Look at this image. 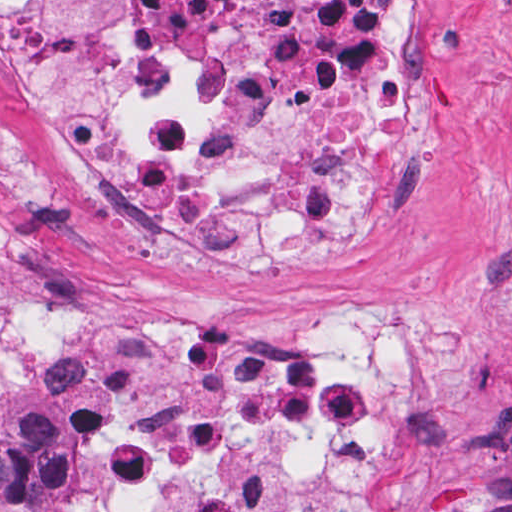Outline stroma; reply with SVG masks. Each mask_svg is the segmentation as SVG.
I'll use <instances>...</instances> for the list:
<instances>
[{
  "mask_svg": "<svg viewBox=\"0 0 512 512\" xmlns=\"http://www.w3.org/2000/svg\"><path fill=\"white\" fill-rule=\"evenodd\" d=\"M363 1L409 24L421 72L413 229L355 271L221 267L92 213L0 62V350L34 317L288 349L381 333L407 343L382 512H512V0ZM107 440L82 389L22 387L0 407V512H107Z\"/></svg>",
  "mask_w": 512,
  "mask_h": 512,
  "instance_id": "35a3bbf8",
  "label": "stroma"
}]
</instances>
